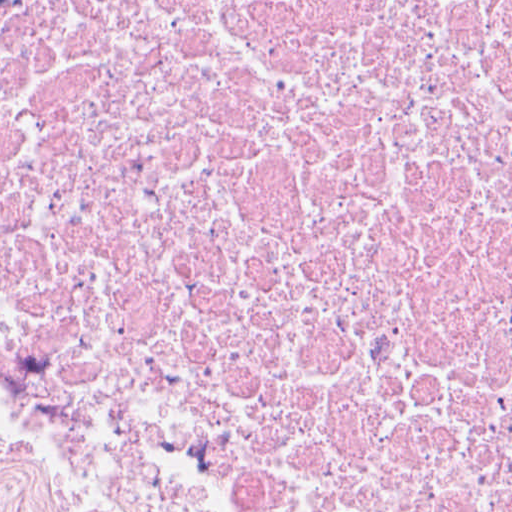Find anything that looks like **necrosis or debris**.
<instances>
[{
	"mask_svg": "<svg viewBox=\"0 0 512 512\" xmlns=\"http://www.w3.org/2000/svg\"><path fill=\"white\" fill-rule=\"evenodd\" d=\"M0 512H512V0H0Z\"/></svg>",
	"mask_w": 512,
	"mask_h": 512,
	"instance_id": "necrosis-or-debris-1",
	"label": "necrosis or debris"
}]
</instances>
